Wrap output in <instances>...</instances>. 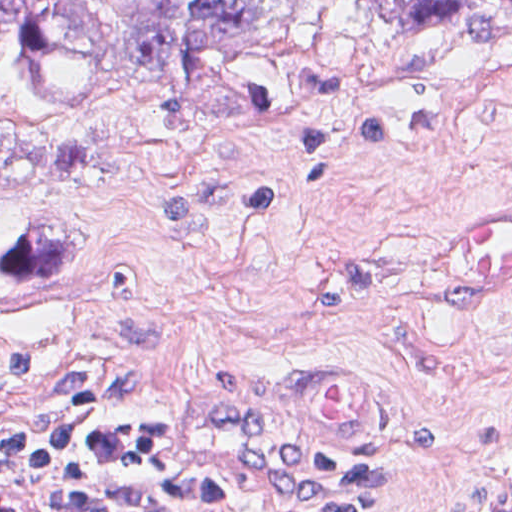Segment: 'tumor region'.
Masks as SVG:
<instances>
[{"label": "tumor region", "mask_w": 512, "mask_h": 512, "mask_svg": "<svg viewBox=\"0 0 512 512\" xmlns=\"http://www.w3.org/2000/svg\"><path fill=\"white\" fill-rule=\"evenodd\" d=\"M311 0H1V198H59L105 165L62 117L121 93L165 97L168 137L234 143L304 95ZM398 34L512 25V0H352Z\"/></svg>", "instance_id": "tumor-region-1"}]
</instances>
